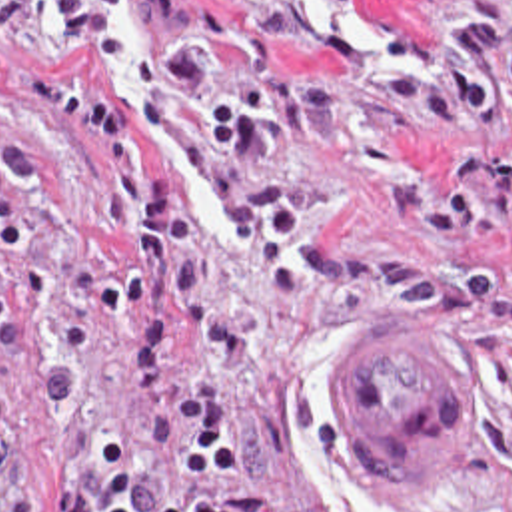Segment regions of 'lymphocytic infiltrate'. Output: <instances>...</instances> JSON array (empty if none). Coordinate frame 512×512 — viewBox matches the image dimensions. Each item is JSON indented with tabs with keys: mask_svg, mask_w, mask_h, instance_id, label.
Segmentation results:
<instances>
[{
	"mask_svg": "<svg viewBox=\"0 0 512 512\" xmlns=\"http://www.w3.org/2000/svg\"><path fill=\"white\" fill-rule=\"evenodd\" d=\"M19 7H45L69 33L111 45L121 25L89 0H0V87L47 111L67 149L123 193L125 237L99 285V317L125 329V378L149 416V454L113 440L79 460L55 512H253V480L221 412L169 366L197 321L223 363L253 357V331L211 293L203 233L173 185H157L135 119L105 83L15 51Z\"/></svg>",
	"mask_w": 512,
	"mask_h": 512,
	"instance_id": "1",
	"label": "lymphocytic infiltrate"
}]
</instances>
